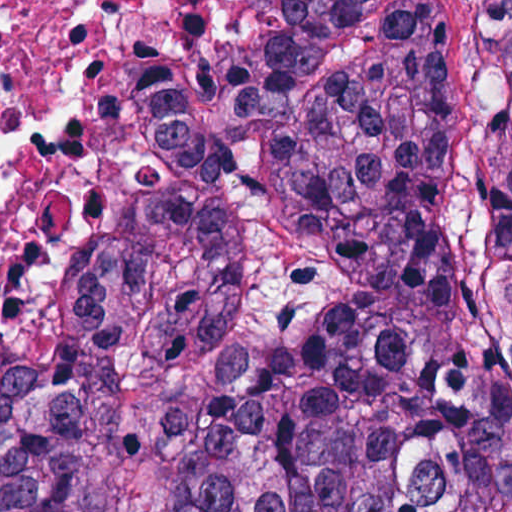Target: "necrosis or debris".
<instances>
[{
  "mask_svg": "<svg viewBox=\"0 0 512 512\" xmlns=\"http://www.w3.org/2000/svg\"><path fill=\"white\" fill-rule=\"evenodd\" d=\"M100 0H0V420L54 376L68 300L146 170V139L84 67Z\"/></svg>",
  "mask_w": 512,
  "mask_h": 512,
  "instance_id": "necrosis-or-debris-1",
  "label": "necrosis or debris"
}]
</instances>
